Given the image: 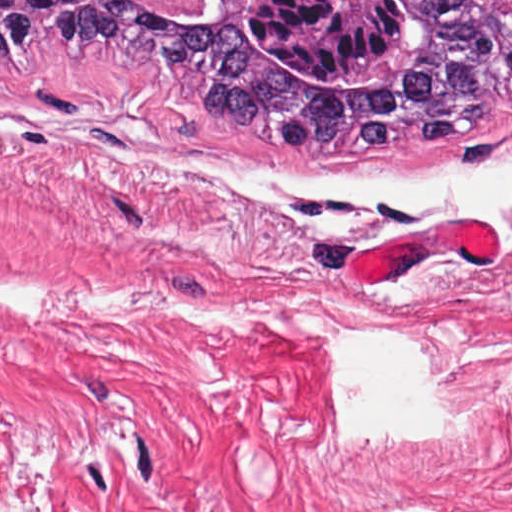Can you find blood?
<instances>
[{
  "instance_id": "obj_1",
  "label": "blood",
  "mask_w": 512,
  "mask_h": 512,
  "mask_svg": "<svg viewBox=\"0 0 512 512\" xmlns=\"http://www.w3.org/2000/svg\"><path fill=\"white\" fill-rule=\"evenodd\" d=\"M461 253H501L491 229L479 218L384 240L345 259L355 281H385L417 260Z\"/></svg>"
}]
</instances>
